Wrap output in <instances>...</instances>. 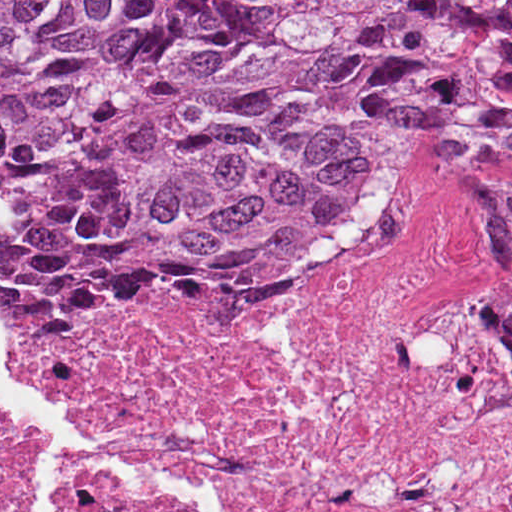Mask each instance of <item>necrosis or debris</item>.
<instances>
[{
    "mask_svg": "<svg viewBox=\"0 0 512 512\" xmlns=\"http://www.w3.org/2000/svg\"><path fill=\"white\" fill-rule=\"evenodd\" d=\"M512 153L438 158L391 184L382 269L213 311L37 327L16 369L79 427L230 493L237 512H512V346L494 229ZM71 512H176L87 470ZM0 512H46L0 442Z\"/></svg>",
    "mask_w": 512,
    "mask_h": 512,
    "instance_id": "1",
    "label": "necrosis or debris"
}]
</instances>
